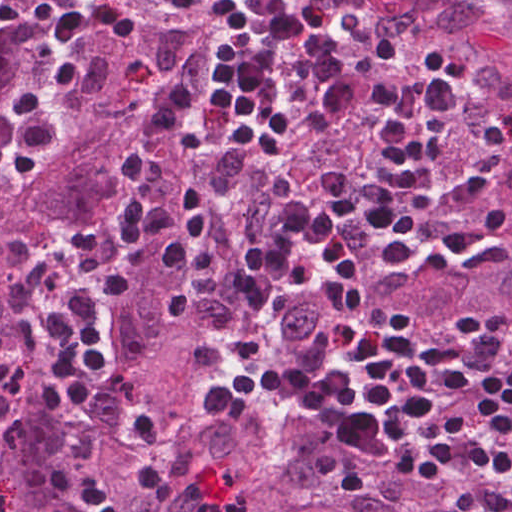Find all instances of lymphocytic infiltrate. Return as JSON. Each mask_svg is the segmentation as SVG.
I'll return each instance as SVG.
<instances>
[{
	"label": "lymphocytic infiltrate",
	"instance_id": "obj_1",
	"mask_svg": "<svg viewBox=\"0 0 512 512\" xmlns=\"http://www.w3.org/2000/svg\"><path fill=\"white\" fill-rule=\"evenodd\" d=\"M473 0H409L410 3L432 7H471Z\"/></svg>",
	"mask_w": 512,
	"mask_h": 512
}]
</instances>
